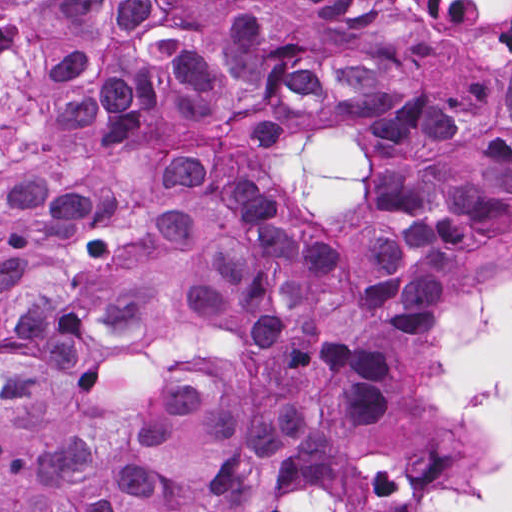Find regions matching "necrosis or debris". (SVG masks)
<instances>
[{
  "mask_svg": "<svg viewBox=\"0 0 512 512\" xmlns=\"http://www.w3.org/2000/svg\"><path fill=\"white\" fill-rule=\"evenodd\" d=\"M427 46L431 78L512 51V0H372ZM113 0H0V174L79 148L102 126Z\"/></svg>",
  "mask_w": 512,
  "mask_h": 512,
  "instance_id": "4bbe7bcc",
  "label": "necrosis or debris"
}]
</instances>
